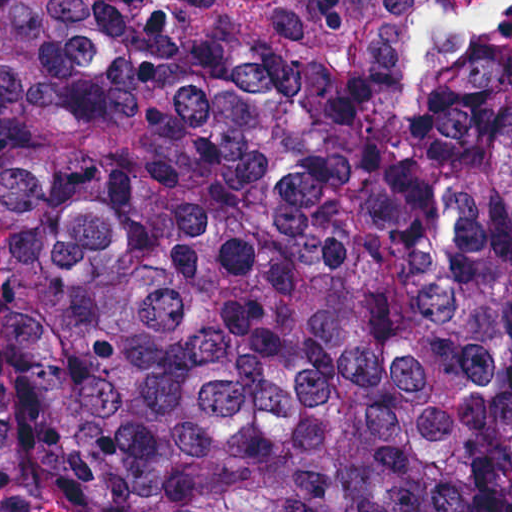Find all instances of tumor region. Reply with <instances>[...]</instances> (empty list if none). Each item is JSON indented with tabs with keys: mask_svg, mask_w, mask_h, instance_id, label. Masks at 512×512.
I'll return each mask as SVG.
<instances>
[{
	"mask_svg": "<svg viewBox=\"0 0 512 512\" xmlns=\"http://www.w3.org/2000/svg\"><path fill=\"white\" fill-rule=\"evenodd\" d=\"M512 512V0H0V505Z\"/></svg>",
	"mask_w": 512,
	"mask_h": 512,
	"instance_id": "1",
	"label": "tumor region"
}]
</instances>
